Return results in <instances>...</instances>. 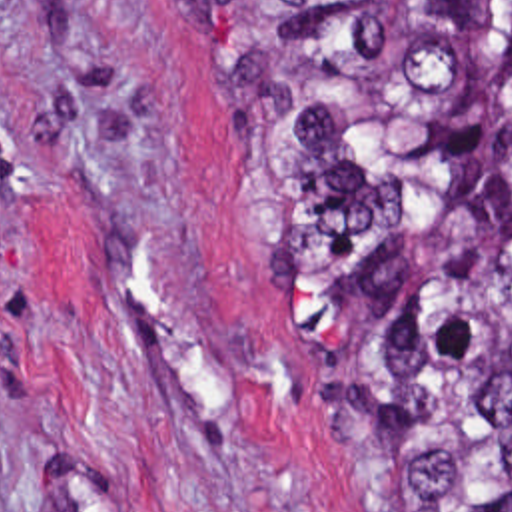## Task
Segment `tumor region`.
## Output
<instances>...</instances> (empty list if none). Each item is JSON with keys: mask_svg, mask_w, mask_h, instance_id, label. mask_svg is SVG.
Returning a JSON list of instances; mask_svg holds the SVG:
<instances>
[{"mask_svg": "<svg viewBox=\"0 0 512 512\" xmlns=\"http://www.w3.org/2000/svg\"><path fill=\"white\" fill-rule=\"evenodd\" d=\"M238 224L382 512H512V0H184Z\"/></svg>", "mask_w": 512, "mask_h": 512, "instance_id": "obj_1", "label": "tumor region"}]
</instances>
